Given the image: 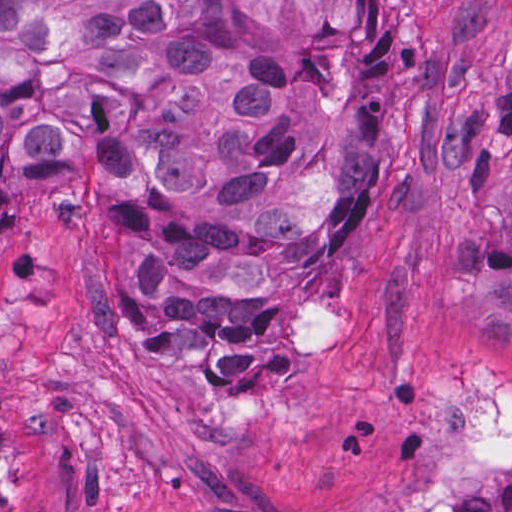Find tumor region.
I'll list each match as a JSON object with an SVG mask.
<instances>
[{
    "instance_id": "1",
    "label": "tumor region",
    "mask_w": 512,
    "mask_h": 512,
    "mask_svg": "<svg viewBox=\"0 0 512 512\" xmlns=\"http://www.w3.org/2000/svg\"><path fill=\"white\" fill-rule=\"evenodd\" d=\"M378 0H0V225L85 209L112 363L235 397L374 186Z\"/></svg>"
}]
</instances>
